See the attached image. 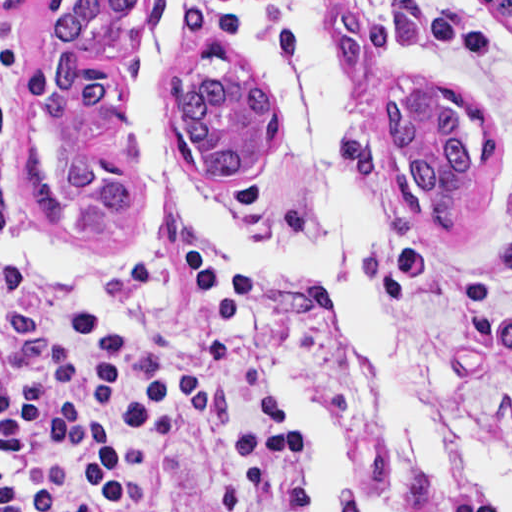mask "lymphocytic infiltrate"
I'll list each match as a JSON object with an SVG mask.
<instances>
[{
	"label": "lymphocytic infiltrate",
	"mask_w": 512,
	"mask_h": 512,
	"mask_svg": "<svg viewBox=\"0 0 512 512\" xmlns=\"http://www.w3.org/2000/svg\"><path fill=\"white\" fill-rule=\"evenodd\" d=\"M18 52L0 31V512H377L255 366L247 255L40 280L10 194Z\"/></svg>",
	"instance_id": "1"
}]
</instances>
